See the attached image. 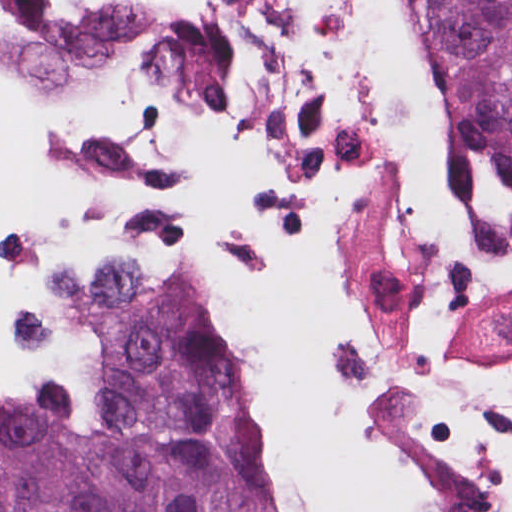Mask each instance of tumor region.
Segmentation results:
<instances>
[{"label": "tumor region", "mask_w": 512, "mask_h": 512, "mask_svg": "<svg viewBox=\"0 0 512 512\" xmlns=\"http://www.w3.org/2000/svg\"><path fill=\"white\" fill-rule=\"evenodd\" d=\"M438 120L512 280V0H418ZM91 370L0 407V512H277L255 385L210 296L79 255L56 283Z\"/></svg>", "instance_id": "obj_1"}]
</instances>
